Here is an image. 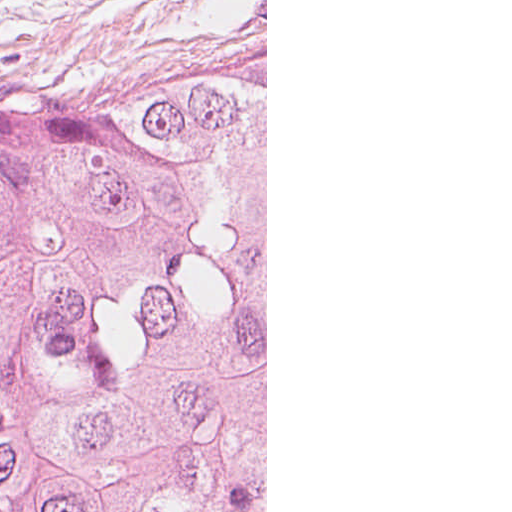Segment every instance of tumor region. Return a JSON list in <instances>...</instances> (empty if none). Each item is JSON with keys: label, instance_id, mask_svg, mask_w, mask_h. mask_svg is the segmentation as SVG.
Masks as SVG:
<instances>
[{"label": "tumor region", "instance_id": "tumor-region-1", "mask_svg": "<svg viewBox=\"0 0 512 512\" xmlns=\"http://www.w3.org/2000/svg\"><path fill=\"white\" fill-rule=\"evenodd\" d=\"M256 63L0 110V512H161Z\"/></svg>", "mask_w": 512, "mask_h": 512}]
</instances>
